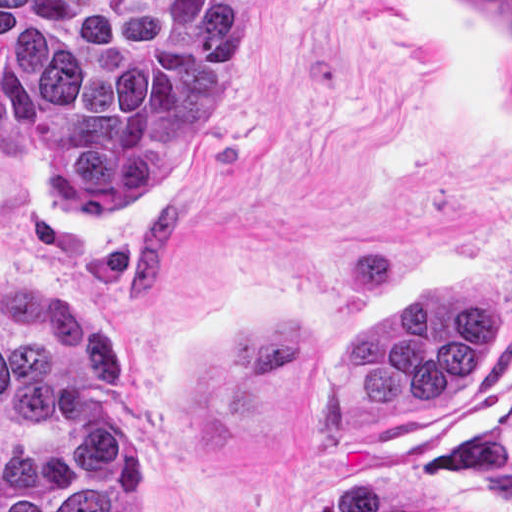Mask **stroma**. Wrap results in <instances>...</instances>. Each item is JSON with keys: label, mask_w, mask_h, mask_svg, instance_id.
<instances>
[{"label": "stroma", "mask_w": 512, "mask_h": 512, "mask_svg": "<svg viewBox=\"0 0 512 512\" xmlns=\"http://www.w3.org/2000/svg\"><path fill=\"white\" fill-rule=\"evenodd\" d=\"M260 1L207 138L129 219H72L0 128V274L122 321L146 512H311L404 481L430 512H512V38L474 1ZM501 283L459 404L366 412L335 362L415 292Z\"/></svg>", "instance_id": "35a3bbf8"}]
</instances>
